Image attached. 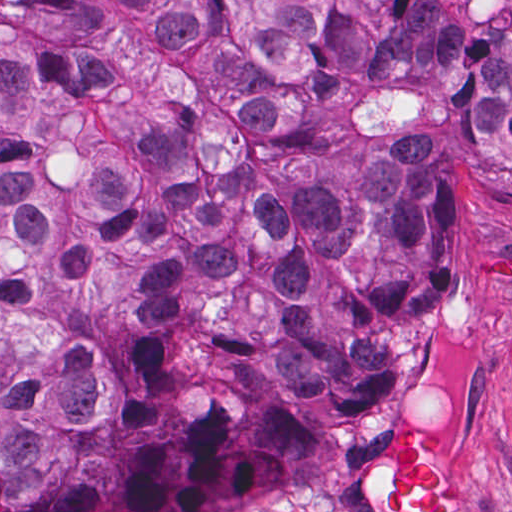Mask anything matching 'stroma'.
<instances>
[{"label":"stroma","instance_id":"35a3bbf8","mask_svg":"<svg viewBox=\"0 0 512 512\" xmlns=\"http://www.w3.org/2000/svg\"><path fill=\"white\" fill-rule=\"evenodd\" d=\"M441 242L447 275L430 301L396 308L380 406L352 445L314 466L286 500L222 512H370L360 493L402 425L450 440L471 512H512V192L468 153L441 156Z\"/></svg>","mask_w":512,"mask_h":512}]
</instances>
